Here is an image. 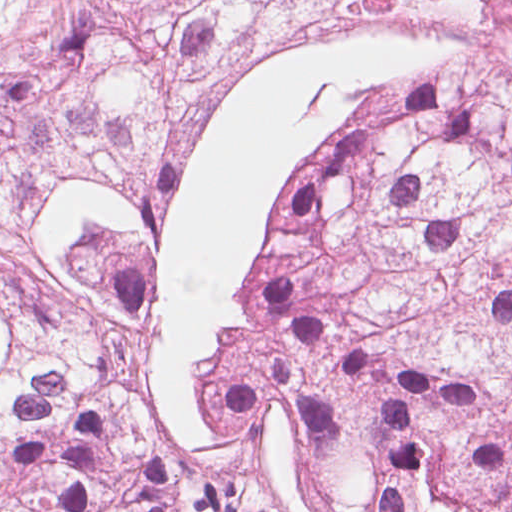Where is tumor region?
Listing matches in <instances>:
<instances>
[{"mask_svg":"<svg viewBox=\"0 0 512 512\" xmlns=\"http://www.w3.org/2000/svg\"><path fill=\"white\" fill-rule=\"evenodd\" d=\"M365 6L479 42L347 131L281 347L184 468L139 375L153 154L233 59ZM0 512H512V0H0Z\"/></svg>","mask_w":512,"mask_h":512,"instance_id":"tumor-region-1","label":"tumor region"}]
</instances>
